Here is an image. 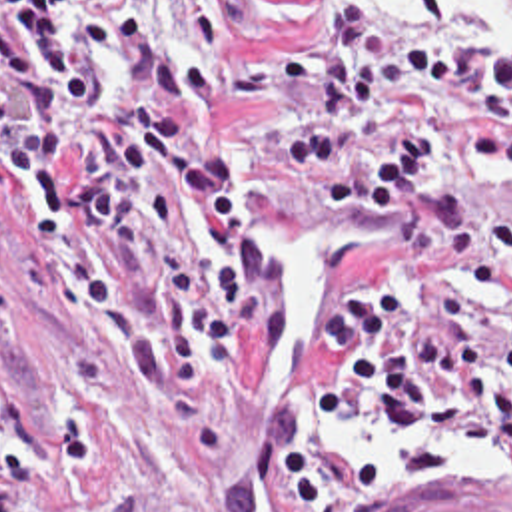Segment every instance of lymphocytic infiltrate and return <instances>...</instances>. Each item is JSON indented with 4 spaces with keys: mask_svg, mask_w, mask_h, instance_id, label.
I'll return each instance as SVG.
<instances>
[{
    "mask_svg": "<svg viewBox=\"0 0 512 512\" xmlns=\"http://www.w3.org/2000/svg\"><path fill=\"white\" fill-rule=\"evenodd\" d=\"M256 0H0V222L20 189L30 304L88 312L90 340L212 466H234L242 336L292 352V276L240 198L226 75L160 35L186 15L224 51ZM420 51L336 11L308 107L280 135L298 195L402 246L358 268L320 318L318 416L376 426L398 474H443L451 450L512 444V206L451 185L457 161L512 173V61L418 0ZM252 448L280 512H330L282 432Z\"/></svg>",
    "mask_w": 512,
    "mask_h": 512,
    "instance_id": "1",
    "label": "lymphocytic infiltrate"
}]
</instances>
